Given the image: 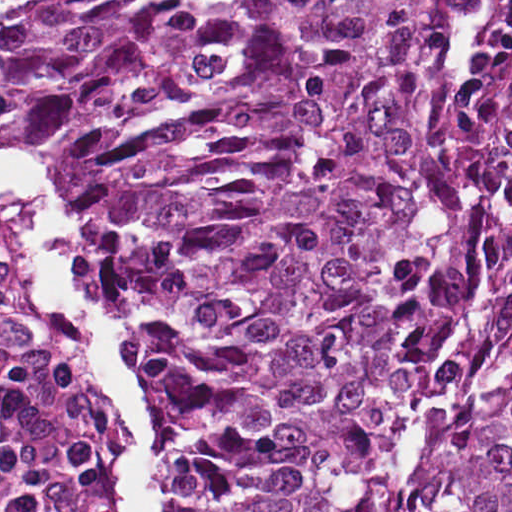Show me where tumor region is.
Returning <instances> with one entry per match:
<instances>
[{"label":"tumor region","instance_id":"e687c5a6","mask_svg":"<svg viewBox=\"0 0 512 512\" xmlns=\"http://www.w3.org/2000/svg\"><path fill=\"white\" fill-rule=\"evenodd\" d=\"M231 0H0V79L167 84ZM87 226L175 382L172 512H512V0H260Z\"/></svg>","mask_w":512,"mask_h":512}]
</instances>
